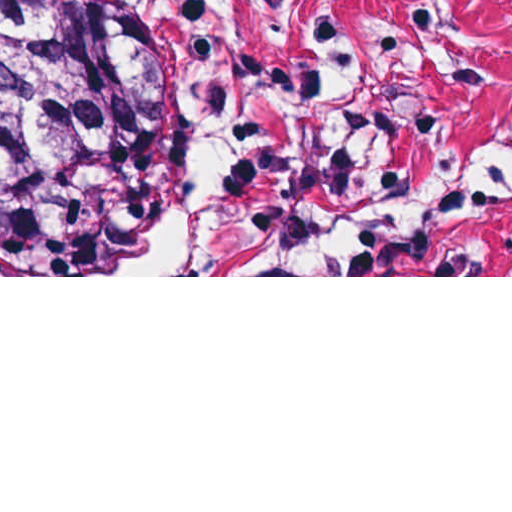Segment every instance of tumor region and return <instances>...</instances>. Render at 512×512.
Here are the masks:
<instances>
[{"label": "tumor region", "instance_id": "obj_1", "mask_svg": "<svg viewBox=\"0 0 512 512\" xmlns=\"http://www.w3.org/2000/svg\"><path fill=\"white\" fill-rule=\"evenodd\" d=\"M179 131L155 36L105 0H0V244L41 240L65 270L176 266Z\"/></svg>", "mask_w": 512, "mask_h": 512}]
</instances>
